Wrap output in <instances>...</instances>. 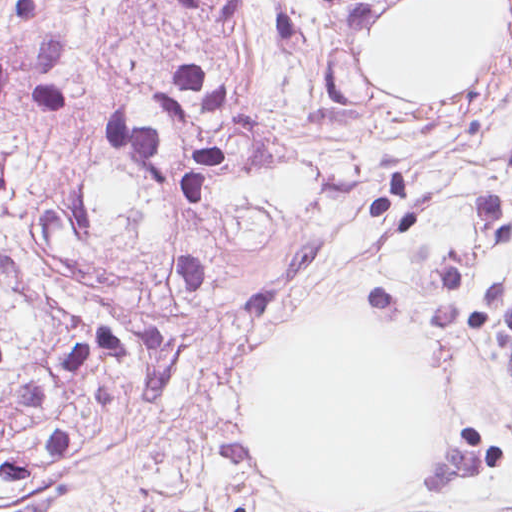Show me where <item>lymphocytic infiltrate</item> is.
I'll list each match as a JSON object with an SVG mask.
<instances>
[{"instance_id":"lymphocytic-infiltrate-1","label":"lymphocytic infiltrate","mask_w":512,"mask_h":512,"mask_svg":"<svg viewBox=\"0 0 512 512\" xmlns=\"http://www.w3.org/2000/svg\"><path fill=\"white\" fill-rule=\"evenodd\" d=\"M0 475L4 477H31V465L22 458L0 452Z\"/></svg>"}]
</instances>
